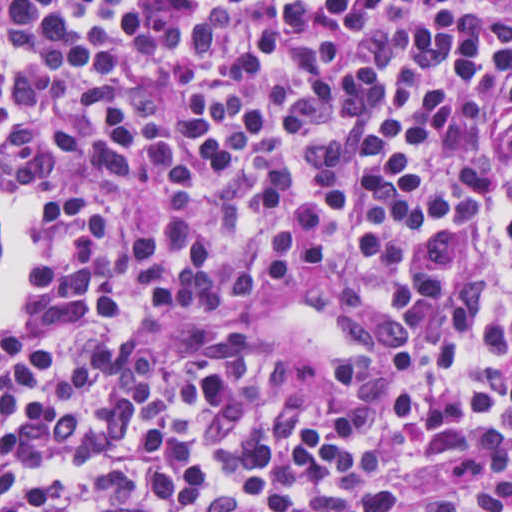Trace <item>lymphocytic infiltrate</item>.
<instances>
[{
    "label": "lymphocytic infiltrate",
    "instance_id": "obj_1",
    "mask_svg": "<svg viewBox=\"0 0 512 512\" xmlns=\"http://www.w3.org/2000/svg\"><path fill=\"white\" fill-rule=\"evenodd\" d=\"M0 512H512V0H0ZM349 279L306 402L167 311Z\"/></svg>",
    "mask_w": 512,
    "mask_h": 512
}]
</instances>
